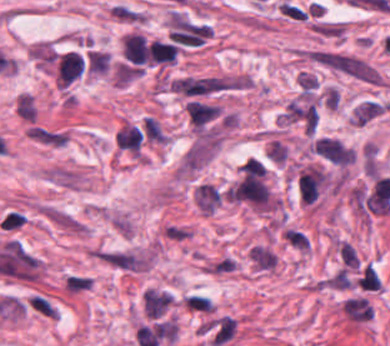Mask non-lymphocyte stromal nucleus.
Returning a JSON list of instances; mask_svg holds the SVG:
<instances>
[{
	"instance_id": "dd21d789",
	"label": "non-lymphocyte stromal nucleus",
	"mask_w": 390,
	"mask_h": 346,
	"mask_svg": "<svg viewBox=\"0 0 390 346\" xmlns=\"http://www.w3.org/2000/svg\"><path fill=\"white\" fill-rule=\"evenodd\" d=\"M220 139L219 128L213 126L199 128L183 155V168L196 170L210 160L219 147Z\"/></svg>"
},
{
	"instance_id": "a72fc3eb",
	"label": "non-lymphocyte stromal nucleus",
	"mask_w": 390,
	"mask_h": 346,
	"mask_svg": "<svg viewBox=\"0 0 390 346\" xmlns=\"http://www.w3.org/2000/svg\"><path fill=\"white\" fill-rule=\"evenodd\" d=\"M312 150L332 164L347 165L354 160L353 151L339 138L321 137Z\"/></svg>"
},
{
	"instance_id": "3746e769",
	"label": "non-lymphocyte stromal nucleus",
	"mask_w": 390,
	"mask_h": 346,
	"mask_svg": "<svg viewBox=\"0 0 390 346\" xmlns=\"http://www.w3.org/2000/svg\"><path fill=\"white\" fill-rule=\"evenodd\" d=\"M27 138L39 145L49 148H62L70 133L64 129L30 123L25 129Z\"/></svg>"
},
{
	"instance_id": "fc2b8d12",
	"label": "non-lymphocyte stromal nucleus",
	"mask_w": 390,
	"mask_h": 346,
	"mask_svg": "<svg viewBox=\"0 0 390 346\" xmlns=\"http://www.w3.org/2000/svg\"><path fill=\"white\" fill-rule=\"evenodd\" d=\"M224 198V191L213 183L200 182L194 192V203L203 213L218 208Z\"/></svg>"
},
{
	"instance_id": "81446118",
	"label": "non-lymphocyte stromal nucleus",
	"mask_w": 390,
	"mask_h": 346,
	"mask_svg": "<svg viewBox=\"0 0 390 346\" xmlns=\"http://www.w3.org/2000/svg\"><path fill=\"white\" fill-rule=\"evenodd\" d=\"M185 108L191 123L203 128L215 117L220 107L202 100L190 99Z\"/></svg>"
},
{
	"instance_id": "7c5642bf",
	"label": "non-lymphocyte stromal nucleus",
	"mask_w": 390,
	"mask_h": 346,
	"mask_svg": "<svg viewBox=\"0 0 390 346\" xmlns=\"http://www.w3.org/2000/svg\"><path fill=\"white\" fill-rule=\"evenodd\" d=\"M25 307L29 311L50 320L59 318L57 306L39 291H31L26 295Z\"/></svg>"
},
{
	"instance_id": "9d01c50a",
	"label": "non-lymphocyte stromal nucleus",
	"mask_w": 390,
	"mask_h": 346,
	"mask_svg": "<svg viewBox=\"0 0 390 346\" xmlns=\"http://www.w3.org/2000/svg\"><path fill=\"white\" fill-rule=\"evenodd\" d=\"M168 293L148 289L142 293V302L145 317L163 315L173 301Z\"/></svg>"
},
{
	"instance_id": "2ac0efb1",
	"label": "non-lymphocyte stromal nucleus",
	"mask_w": 390,
	"mask_h": 346,
	"mask_svg": "<svg viewBox=\"0 0 390 346\" xmlns=\"http://www.w3.org/2000/svg\"><path fill=\"white\" fill-rule=\"evenodd\" d=\"M140 131L144 143L163 144L168 135L159 120L153 117H145L140 122Z\"/></svg>"
},
{
	"instance_id": "616ff342",
	"label": "non-lymphocyte stromal nucleus",
	"mask_w": 390,
	"mask_h": 346,
	"mask_svg": "<svg viewBox=\"0 0 390 346\" xmlns=\"http://www.w3.org/2000/svg\"><path fill=\"white\" fill-rule=\"evenodd\" d=\"M250 259L259 269L267 271L277 267L278 259L272 248L262 245H254L249 251Z\"/></svg>"
}]
</instances>
